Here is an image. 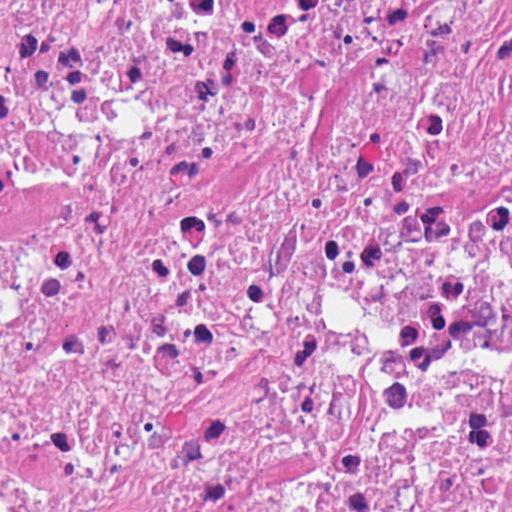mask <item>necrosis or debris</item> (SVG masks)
<instances>
[{"instance_id":"obj_1","label":"necrosis or debris","mask_w":512,"mask_h":512,"mask_svg":"<svg viewBox=\"0 0 512 512\" xmlns=\"http://www.w3.org/2000/svg\"><path fill=\"white\" fill-rule=\"evenodd\" d=\"M1 512H512V0H1Z\"/></svg>"}]
</instances>
